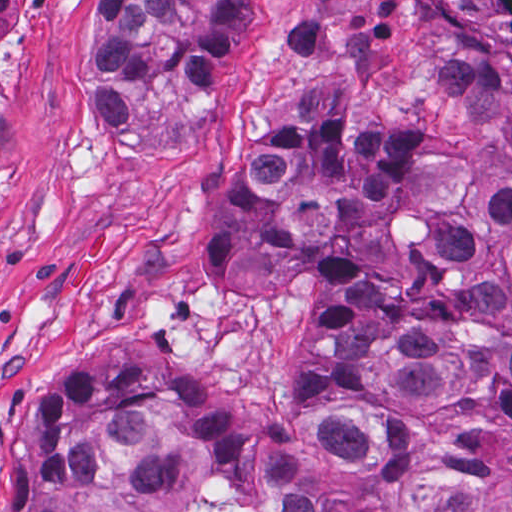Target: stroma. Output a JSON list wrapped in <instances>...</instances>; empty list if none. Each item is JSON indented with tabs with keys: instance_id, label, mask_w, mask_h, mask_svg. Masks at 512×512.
Returning a JSON list of instances; mask_svg holds the SVG:
<instances>
[{
	"instance_id": "1",
	"label": "stroma",
	"mask_w": 512,
	"mask_h": 512,
	"mask_svg": "<svg viewBox=\"0 0 512 512\" xmlns=\"http://www.w3.org/2000/svg\"><path fill=\"white\" fill-rule=\"evenodd\" d=\"M107 0H37L14 31L1 119V444L29 387L112 310L135 311L203 395L283 413L308 305L229 302L208 287L203 241L213 176L283 99L328 87L355 117L443 129L483 181L512 184V126L450 84L426 0H251L217 100L176 77L135 105L120 146H96ZM484 475L460 512H497Z\"/></svg>"
}]
</instances>
